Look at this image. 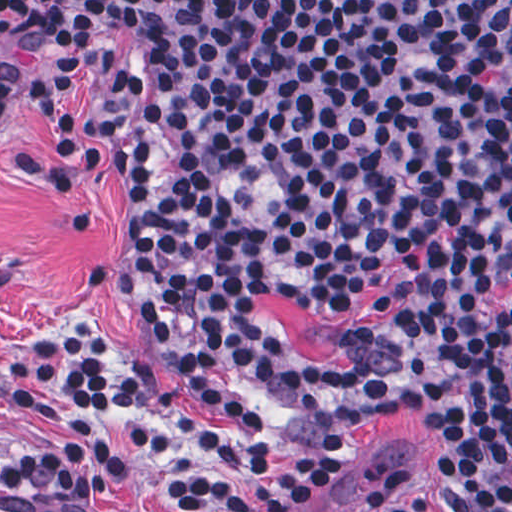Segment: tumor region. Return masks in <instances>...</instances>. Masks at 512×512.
I'll return each mask as SVG.
<instances>
[{"instance_id":"tumor-region-1","label":"tumor region","mask_w":512,"mask_h":512,"mask_svg":"<svg viewBox=\"0 0 512 512\" xmlns=\"http://www.w3.org/2000/svg\"><path fill=\"white\" fill-rule=\"evenodd\" d=\"M494 368L504 375L512 386V322L503 330L493 351Z\"/></svg>"}]
</instances>
